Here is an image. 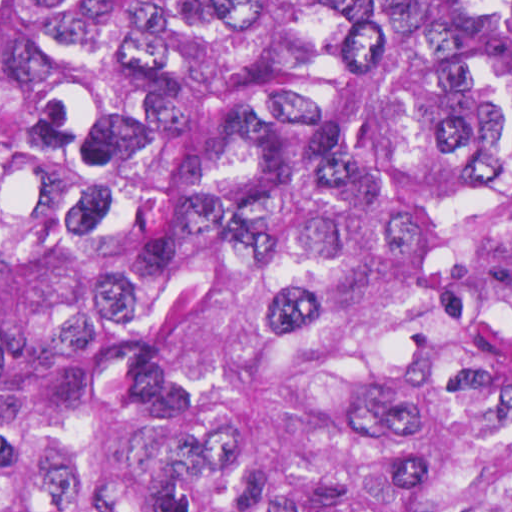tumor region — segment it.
<instances>
[{
	"instance_id": "e687c5a6",
	"label": "tumor region",
	"mask_w": 512,
	"mask_h": 512,
	"mask_svg": "<svg viewBox=\"0 0 512 512\" xmlns=\"http://www.w3.org/2000/svg\"><path fill=\"white\" fill-rule=\"evenodd\" d=\"M0 512H512V0H0Z\"/></svg>"
}]
</instances>
